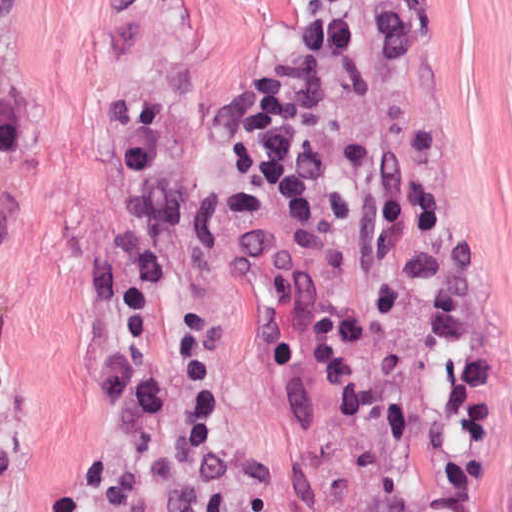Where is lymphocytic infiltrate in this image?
<instances>
[{
	"label": "lymphocytic infiltrate",
	"instance_id": "1",
	"mask_svg": "<svg viewBox=\"0 0 512 512\" xmlns=\"http://www.w3.org/2000/svg\"><path fill=\"white\" fill-rule=\"evenodd\" d=\"M54 512H263L177 334L121 310Z\"/></svg>",
	"mask_w": 512,
	"mask_h": 512
}]
</instances>
